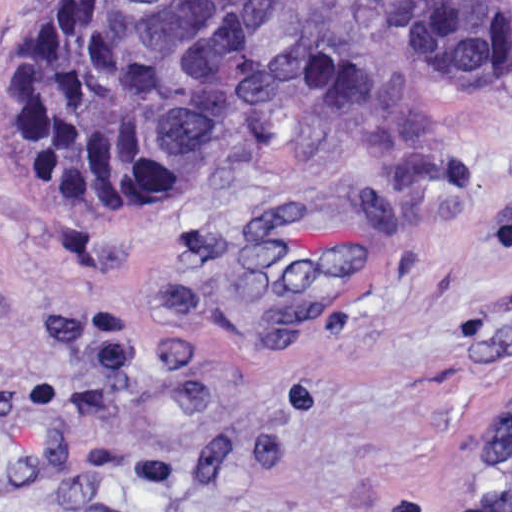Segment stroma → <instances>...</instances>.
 <instances>
[{"mask_svg":"<svg viewBox=\"0 0 512 512\" xmlns=\"http://www.w3.org/2000/svg\"><path fill=\"white\" fill-rule=\"evenodd\" d=\"M18 1L0 512H470L512 392V69L411 58L419 0H217L221 153L107 229L6 153Z\"/></svg>","mask_w":512,"mask_h":512,"instance_id":"1","label":"stroma"}]
</instances>
